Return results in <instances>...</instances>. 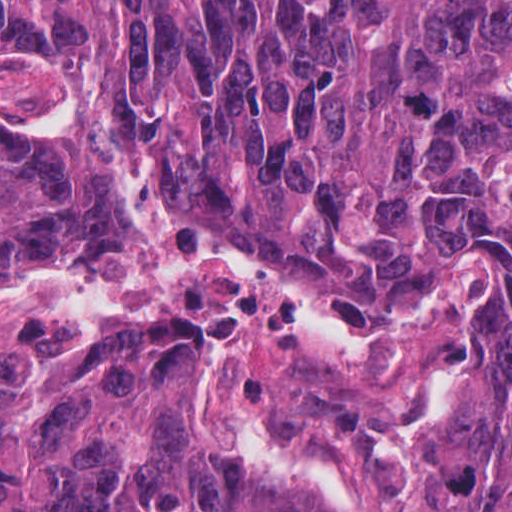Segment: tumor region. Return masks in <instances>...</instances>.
I'll use <instances>...</instances> for the list:
<instances>
[{"label":"tumor region","instance_id":"tumor-region-1","mask_svg":"<svg viewBox=\"0 0 512 512\" xmlns=\"http://www.w3.org/2000/svg\"><path fill=\"white\" fill-rule=\"evenodd\" d=\"M88 106L194 238L388 330L456 257L492 269L429 512H512V0H0V63ZM119 216L82 163L0 129V283L103 262ZM202 329L109 322L0 373V512H348L191 397Z\"/></svg>","mask_w":512,"mask_h":512}]
</instances>
